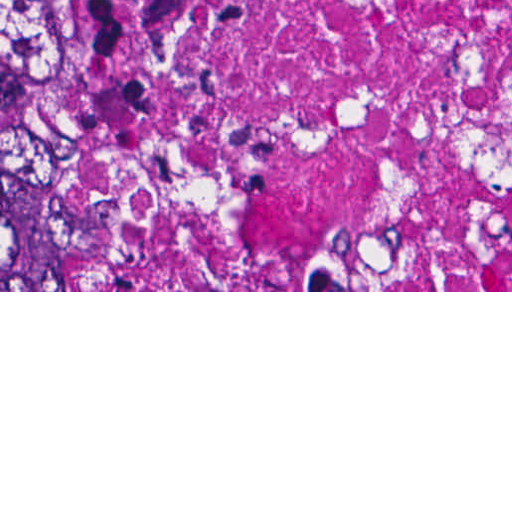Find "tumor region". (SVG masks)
<instances>
[{
  "instance_id": "1",
  "label": "tumor region",
  "mask_w": 512,
  "mask_h": 512,
  "mask_svg": "<svg viewBox=\"0 0 512 512\" xmlns=\"http://www.w3.org/2000/svg\"><path fill=\"white\" fill-rule=\"evenodd\" d=\"M45 0H0V113H93L42 53ZM113 232L84 121L33 114L0 127V291H94Z\"/></svg>"
}]
</instances>
